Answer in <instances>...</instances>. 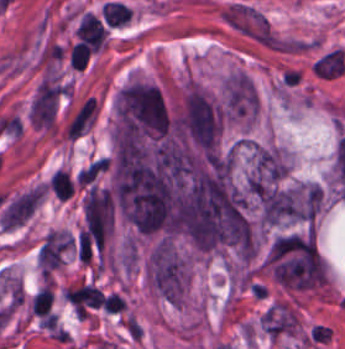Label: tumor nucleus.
Segmentation results:
<instances>
[{
  "instance_id": "2f306a5c",
  "label": "tumor nucleus",
  "mask_w": 345,
  "mask_h": 349,
  "mask_svg": "<svg viewBox=\"0 0 345 349\" xmlns=\"http://www.w3.org/2000/svg\"><path fill=\"white\" fill-rule=\"evenodd\" d=\"M260 217L268 225L296 220L300 205L295 190L270 186L259 199Z\"/></svg>"
},
{
  "instance_id": "8643909e",
  "label": "tumor nucleus",
  "mask_w": 345,
  "mask_h": 349,
  "mask_svg": "<svg viewBox=\"0 0 345 349\" xmlns=\"http://www.w3.org/2000/svg\"><path fill=\"white\" fill-rule=\"evenodd\" d=\"M42 190L31 189L9 204L0 217V225L11 228L20 225L41 200Z\"/></svg>"
}]
</instances>
